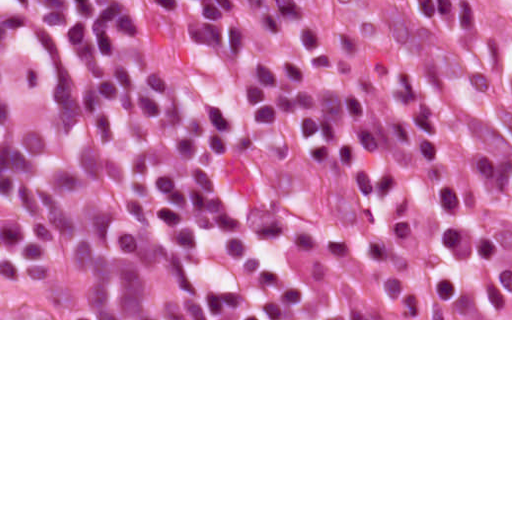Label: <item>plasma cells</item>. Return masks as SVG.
I'll use <instances>...</instances> for the list:
<instances>
[{
  "label": "plasma cells",
  "instance_id": "9512152a",
  "mask_svg": "<svg viewBox=\"0 0 512 512\" xmlns=\"http://www.w3.org/2000/svg\"><path fill=\"white\" fill-rule=\"evenodd\" d=\"M0 38L183 210L302 260H382L458 218L453 0L382 29L297 0H0Z\"/></svg>",
  "mask_w": 512,
  "mask_h": 512
}]
</instances>
